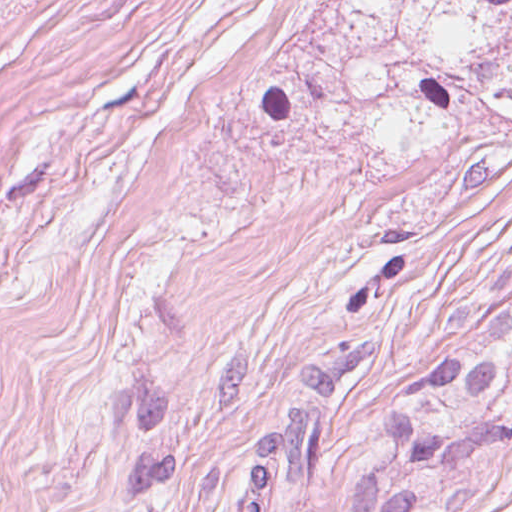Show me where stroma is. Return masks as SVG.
<instances>
[{
  "instance_id": "stroma-1",
  "label": "stroma",
  "mask_w": 512,
  "mask_h": 512,
  "mask_svg": "<svg viewBox=\"0 0 512 512\" xmlns=\"http://www.w3.org/2000/svg\"><path fill=\"white\" fill-rule=\"evenodd\" d=\"M512 273V120L142 0L0 438V512H231L304 356L333 419ZM451 512H512V481Z\"/></svg>"
}]
</instances>
